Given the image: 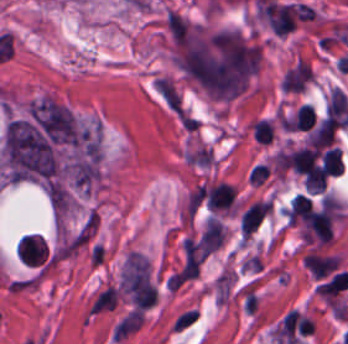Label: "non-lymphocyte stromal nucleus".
<instances>
[{
	"label": "non-lymphocyte stromal nucleus",
	"mask_w": 348,
	"mask_h": 344,
	"mask_svg": "<svg viewBox=\"0 0 348 344\" xmlns=\"http://www.w3.org/2000/svg\"><path fill=\"white\" fill-rule=\"evenodd\" d=\"M197 320L196 308H188L175 316L170 325V329L177 333H184L190 329Z\"/></svg>",
	"instance_id": "dd21d789"
}]
</instances>
